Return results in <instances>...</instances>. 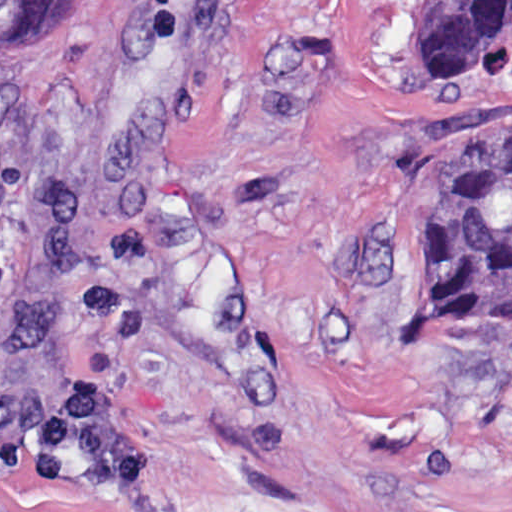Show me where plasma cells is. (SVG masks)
Returning <instances> with one entry per match:
<instances>
[{
    "label": "plasma cells",
    "mask_w": 512,
    "mask_h": 512,
    "mask_svg": "<svg viewBox=\"0 0 512 512\" xmlns=\"http://www.w3.org/2000/svg\"><path fill=\"white\" fill-rule=\"evenodd\" d=\"M0 462L74 487L142 476V462L118 434L105 394L83 381L68 387L52 412L0 440Z\"/></svg>",
    "instance_id": "9512152a"
}]
</instances>
